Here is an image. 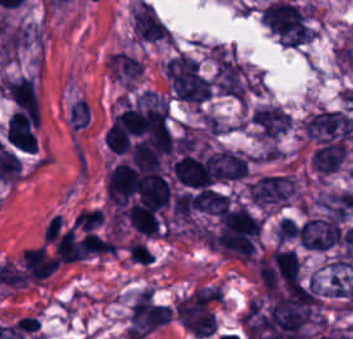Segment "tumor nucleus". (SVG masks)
Returning a JSON list of instances; mask_svg holds the SVG:
<instances>
[{"mask_svg":"<svg viewBox=\"0 0 353 339\" xmlns=\"http://www.w3.org/2000/svg\"><path fill=\"white\" fill-rule=\"evenodd\" d=\"M1 90L13 107L26 110H38L40 107L36 82L27 74L3 77Z\"/></svg>","mask_w":353,"mask_h":339,"instance_id":"obj_5","label":"tumor nucleus"},{"mask_svg":"<svg viewBox=\"0 0 353 339\" xmlns=\"http://www.w3.org/2000/svg\"><path fill=\"white\" fill-rule=\"evenodd\" d=\"M258 139H274L291 126L292 117L281 107L273 104L253 109L251 115Z\"/></svg>","mask_w":353,"mask_h":339,"instance_id":"obj_6","label":"tumor nucleus"},{"mask_svg":"<svg viewBox=\"0 0 353 339\" xmlns=\"http://www.w3.org/2000/svg\"><path fill=\"white\" fill-rule=\"evenodd\" d=\"M129 23L132 40L140 43L170 45V30L153 7L137 1L131 10Z\"/></svg>","mask_w":353,"mask_h":339,"instance_id":"obj_2","label":"tumor nucleus"},{"mask_svg":"<svg viewBox=\"0 0 353 339\" xmlns=\"http://www.w3.org/2000/svg\"><path fill=\"white\" fill-rule=\"evenodd\" d=\"M107 65L113 81L132 89L144 72L140 61L124 51L109 56Z\"/></svg>","mask_w":353,"mask_h":339,"instance_id":"obj_7","label":"tumor nucleus"},{"mask_svg":"<svg viewBox=\"0 0 353 339\" xmlns=\"http://www.w3.org/2000/svg\"><path fill=\"white\" fill-rule=\"evenodd\" d=\"M8 143L23 151H37L38 111L16 109L6 124Z\"/></svg>","mask_w":353,"mask_h":339,"instance_id":"obj_3","label":"tumor nucleus"},{"mask_svg":"<svg viewBox=\"0 0 353 339\" xmlns=\"http://www.w3.org/2000/svg\"><path fill=\"white\" fill-rule=\"evenodd\" d=\"M90 120V109L88 102L85 99H78L74 102L70 113H69V123L71 127L76 130H80L87 124Z\"/></svg>","mask_w":353,"mask_h":339,"instance_id":"obj_8","label":"tumor nucleus"},{"mask_svg":"<svg viewBox=\"0 0 353 339\" xmlns=\"http://www.w3.org/2000/svg\"><path fill=\"white\" fill-rule=\"evenodd\" d=\"M300 243L310 250H329L340 240V223L332 217L315 218L299 228Z\"/></svg>","mask_w":353,"mask_h":339,"instance_id":"obj_4","label":"tumor nucleus"},{"mask_svg":"<svg viewBox=\"0 0 353 339\" xmlns=\"http://www.w3.org/2000/svg\"><path fill=\"white\" fill-rule=\"evenodd\" d=\"M249 200L263 208H282L296 194L295 181L287 175H261L247 184Z\"/></svg>","mask_w":353,"mask_h":339,"instance_id":"obj_1","label":"tumor nucleus"}]
</instances>
